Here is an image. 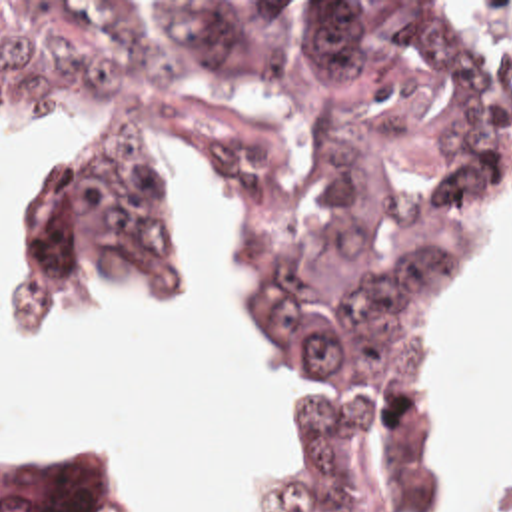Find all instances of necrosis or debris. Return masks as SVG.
<instances>
[{"label": "necrosis or debris", "mask_w": 512, "mask_h": 512, "mask_svg": "<svg viewBox=\"0 0 512 512\" xmlns=\"http://www.w3.org/2000/svg\"><path fill=\"white\" fill-rule=\"evenodd\" d=\"M473 512H512V497L503 499V501H495V503H487Z\"/></svg>", "instance_id": "1"}]
</instances>
